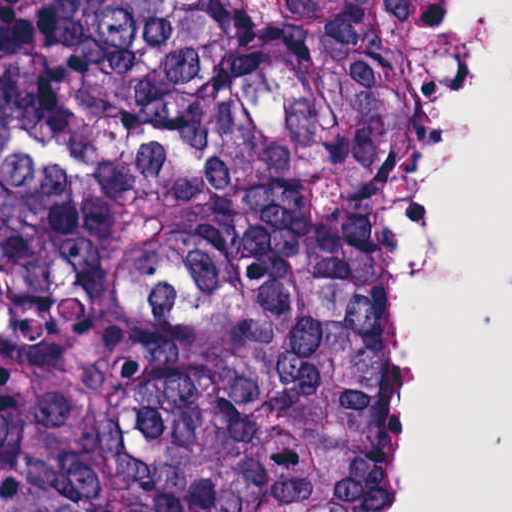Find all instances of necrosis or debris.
Masks as SVG:
<instances>
[{
    "label": "necrosis or debris",
    "instance_id": "necrosis-or-debris-1",
    "mask_svg": "<svg viewBox=\"0 0 512 512\" xmlns=\"http://www.w3.org/2000/svg\"><path fill=\"white\" fill-rule=\"evenodd\" d=\"M466 1L435 0V27L419 89L453 41ZM401 129L381 173L378 191L375 307L368 348V430L384 486L385 512H403V468L391 416V177Z\"/></svg>",
    "mask_w": 512,
    "mask_h": 512
}]
</instances>
